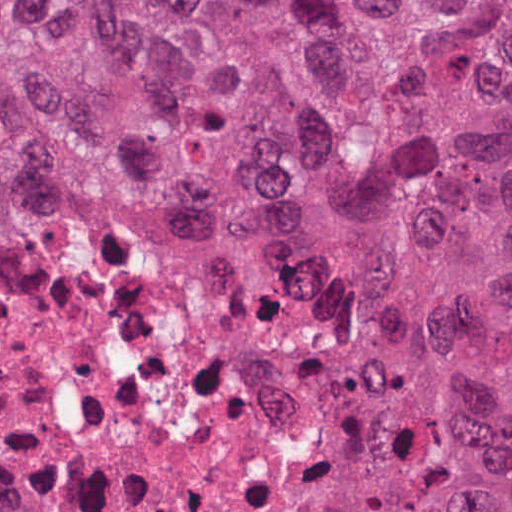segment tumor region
Listing matches in <instances>:
<instances>
[{
  "label": "tumor region",
  "mask_w": 512,
  "mask_h": 512,
  "mask_svg": "<svg viewBox=\"0 0 512 512\" xmlns=\"http://www.w3.org/2000/svg\"><path fill=\"white\" fill-rule=\"evenodd\" d=\"M354 258L342 512H512V1H0V252Z\"/></svg>",
  "instance_id": "obj_1"
}]
</instances>
